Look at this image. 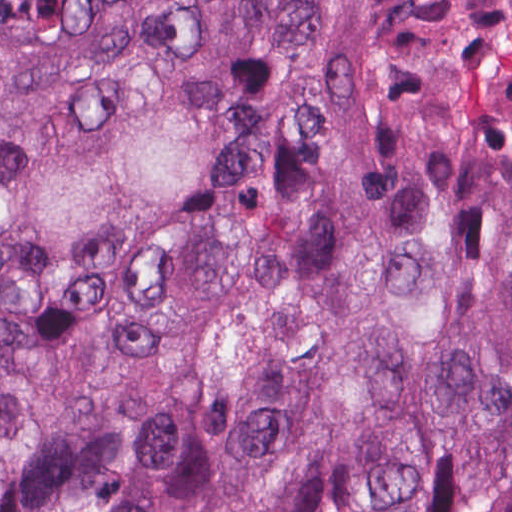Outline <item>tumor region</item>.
<instances>
[{"mask_svg":"<svg viewBox=\"0 0 512 512\" xmlns=\"http://www.w3.org/2000/svg\"><path fill=\"white\" fill-rule=\"evenodd\" d=\"M270 22L367 36L440 109L367 171L304 74L158 248ZM0 88L76 250L152 252L0 326V512H512V0H0ZM56 290L0 127V306Z\"/></svg>","mask_w":512,"mask_h":512,"instance_id":"e687c5a6","label":"tumor region"}]
</instances>
